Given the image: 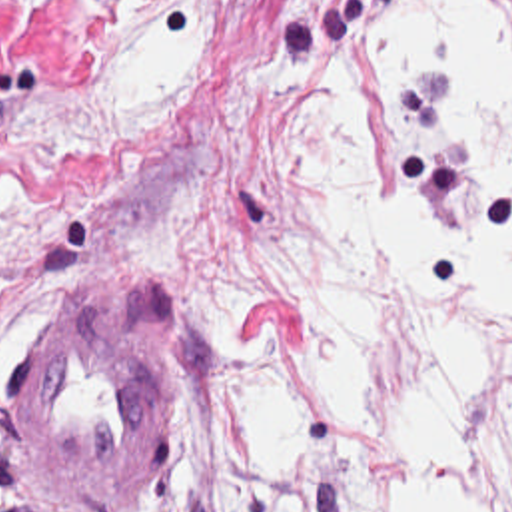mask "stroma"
Segmentation results:
<instances>
[{"label":"stroma","instance_id":"35a3bbf8","mask_svg":"<svg viewBox=\"0 0 512 512\" xmlns=\"http://www.w3.org/2000/svg\"><path fill=\"white\" fill-rule=\"evenodd\" d=\"M195 4V70L161 115L81 149H21L33 125L103 94L147 20ZM510 4L512 0H468ZM399 0H0L1 512H137L159 457L183 512H255L211 465L249 345L325 335L295 287L289 189L349 60V102L393 193L391 106L369 28ZM141 129V131H139ZM91 287L147 317L169 355V407L139 477L101 503L49 495L17 439L11 391L45 301Z\"/></svg>","mask_w":512,"mask_h":512}]
</instances>
